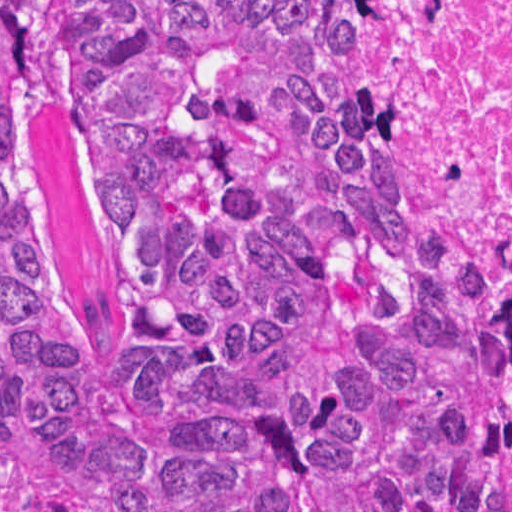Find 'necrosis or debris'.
Returning <instances> with one entry per match:
<instances>
[{
	"label": "necrosis or debris",
	"instance_id": "necrosis-or-debris-1",
	"mask_svg": "<svg viewBox=\"0 0 512 512\" xmlns=\"http://www.w3.org/2000/svg\"><path fill=\"white\" fill-rule=\"evenodd\" d=\"M370 109L419 138L512 272V0H322Z\"/></svg>",
	"mask_w": 512,
	"mask_h": 512
}]
</instances>
